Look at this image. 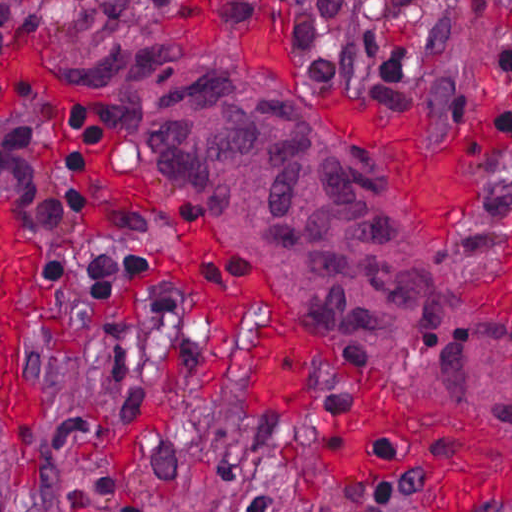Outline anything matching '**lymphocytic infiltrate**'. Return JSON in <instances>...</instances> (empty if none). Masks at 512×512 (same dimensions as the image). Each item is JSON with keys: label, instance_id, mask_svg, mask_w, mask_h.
I'll use <instances>...</instances> for the list:
<instances>
[{"label": "lymphocytic infiltrate", "instance_id": "obj_1", "mask_svg": "<svg viewBox=\"0 0 512 512\" xmlns=\"http://www.w3.org/2000/svg\"><path fill=\"white\" fill-rule=\"evenodd\" d=\"M138 0H99L109 15ZM220 19L239 26L275 21L289 27L303 52L304 71L315 84H332L343 69L342 22L347 0H201ZM426 0H371L359 27L358 46L392 86L429 93L455 113L497 123L512 134V103L468 80L466 45L471 34L503 20L512 0H453L447 15L429 24ZM248 20L252 23H238ZM105 130L79 107L31 91H11L2 131L4 157L39 209L47 239L51 279L78 285L107 300L142 290L155 272V257L134 249L86 261L78 240L88 222V188L94 147ZM256 469V489L238 512H279V479ZM0 512L7 501L0 494Z\"/></svg>", "mask_w": 512, "mask_h": 512}]
</instances>
